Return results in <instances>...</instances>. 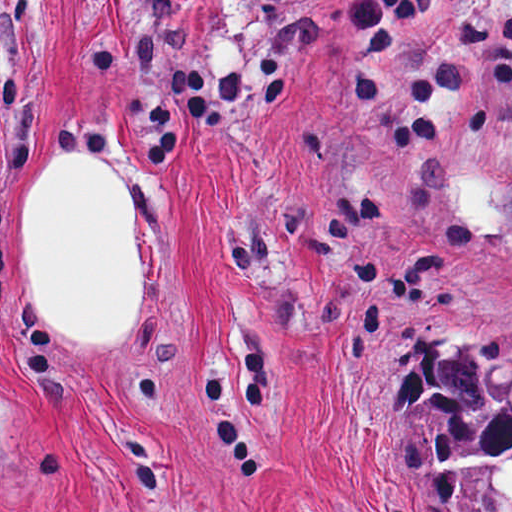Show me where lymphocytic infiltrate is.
Wrapping results in <instances>:
<instances>
[{
    "instance_id": "lymphocytic-infiltrate-1",
    "label": "lymphocytic infiltrate",
    "mask_w": 512,
    "mask_h": 512,
    "mask_svg": "<svg viewBox=\"0 0 512 512\" xmlns=\"http://www.w3.org/2000/svg\"><path fill=\"white\" fill-rule=\"evenodd\" d=\"M451 0H350L354 52L368 71L400 69L417 60Z\"/></svg>"
}]
</instances>
